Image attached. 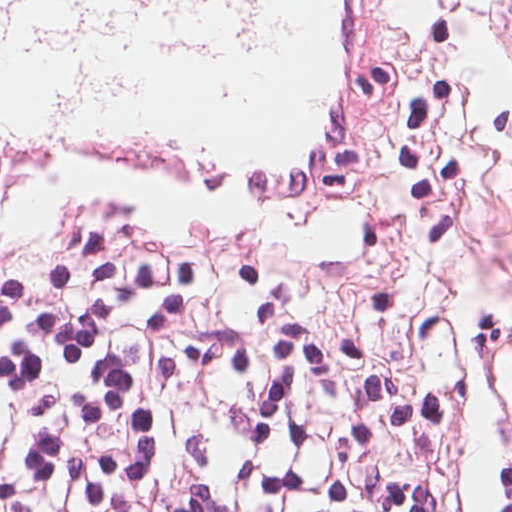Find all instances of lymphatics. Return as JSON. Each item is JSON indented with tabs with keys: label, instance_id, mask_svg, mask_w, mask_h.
Masks as SVG:
<instances>
[{
	"label": "lymphatics",
	"instance_id": "788a7518",
	"mask_svg": "<svg viewBox=\"0 0 512 512\" xmlns=\"http://www.w3.org/2000/svg\"><path fill=\"white\" fill-rule=\"evenodd\" d=\"M268 2L0 0V57L27 55L58 108L94 114L145 72L248 51Z\"/></svg>",
	"mask_w": 512,
	"mask_h": 512
}]
</instances>
